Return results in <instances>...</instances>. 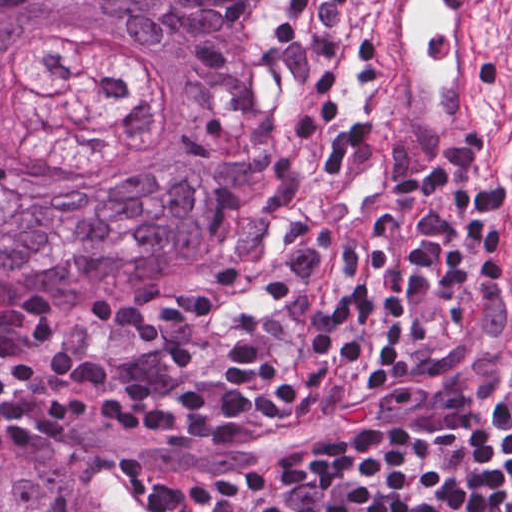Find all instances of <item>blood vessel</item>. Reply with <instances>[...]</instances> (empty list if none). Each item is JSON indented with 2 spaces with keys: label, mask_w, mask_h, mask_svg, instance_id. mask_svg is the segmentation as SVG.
I'll return each mask as SVG.
<instances>
[{
  "label": "blood vessel",
  "mask_w": 512,
  "mask_h": 512,
  "mask_svg": "<svg viewBox=\"0 0 512 512\" xmlns=\"http://www.w3.org/2000/svg\"><path fill=\"white\" fill-rule=\"evenodd\" d=\"M509 51L506 0H351L338 76L395 161L447 172L481 131Z\"/></svg>",
  "instance_id": "8fb6f2fc"
}]
</instances>
